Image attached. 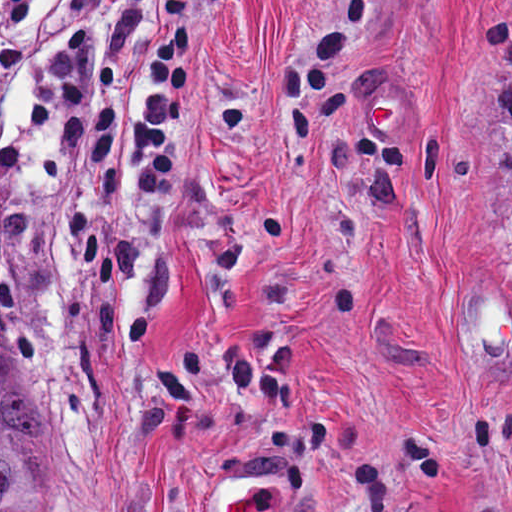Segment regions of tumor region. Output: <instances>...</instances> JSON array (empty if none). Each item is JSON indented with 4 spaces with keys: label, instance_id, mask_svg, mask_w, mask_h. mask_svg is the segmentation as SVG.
<instances>
[{
    "label": "tumor region",
    "instance_id": "obj_1",
    "mask_svg": "<svg viewBox=\"0 0 512 512\" xmlns=\"http://www.w3.org/2000/svg\"><path fill=\"white\" fill-rule=\"evenodd\" d=\"M48 431L36 399L15 368L0 362V512H42L34 485L15 457L19 435Z\"/></svg>",
    "mask_w": 512,
    "mask_h": 512
}]
</instances>
